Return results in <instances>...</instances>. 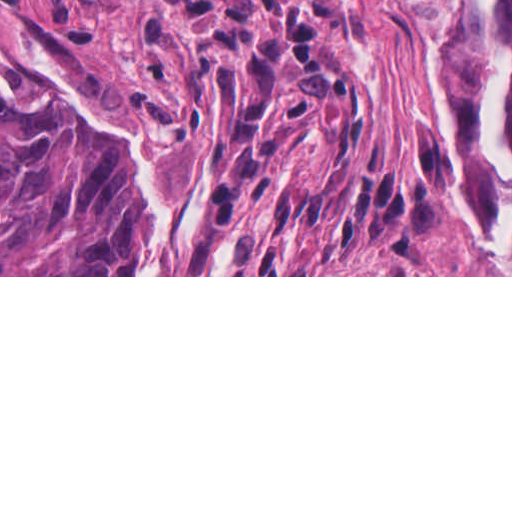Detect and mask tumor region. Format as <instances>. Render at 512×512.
Listing matches in <instances>:
<instances>
[{
	"label": "tumor region",
	"instance_id": "1",
	"mask_svg": "<svg viewBox=\"0 0 512 512\" xmlns=\"http://www.w3.org/2000/svg\"><path fill=\"white\" fill-rule=\"evenodd\" d=\"M125 1L181 19L212 123L207 227L184 275H335L331 253L407 249L436 227L440 190L363 161L364 92L319 18L336 0ZM492 29L510 57L500 117L512 142V0H497ZM427 38L488 235L497 164L481 125L489 54L475 0H461L449 36ZM143 225L118 150L39 87L0 91V275H123Z\"/></svg>",
	"mask_w": 512,
	"mask_h": 512
}]
</instances>
